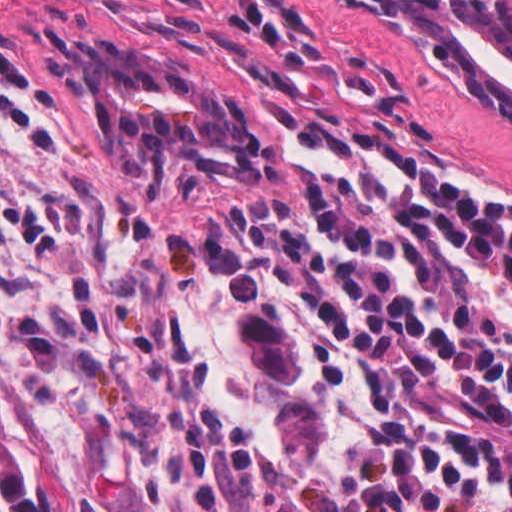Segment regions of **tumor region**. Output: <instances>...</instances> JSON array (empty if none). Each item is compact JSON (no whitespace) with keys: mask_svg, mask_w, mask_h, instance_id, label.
<instances>
[{"mask_svg":"<svg viewBox=\"0 0 512 512\" xmlns=\"http://www.w3.org/2000/svg\"><path fill=\"white\" fill-rule=\"evenodd\" d=\"M64 91L114 167H150L189 155L243 153L258 117L107 40L69 43ZM33 484L8 438L0 394V512H90L61 480L40 432L26 419Z\"/></svg>","mask_w":512,"mask_h":512,"instance_id":"1","label":"tumor region"}]
</instances>
